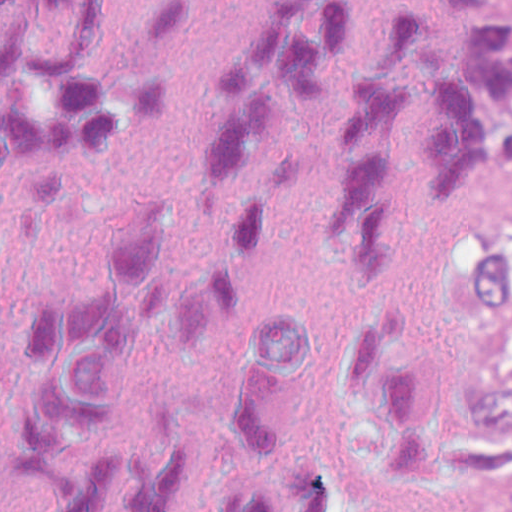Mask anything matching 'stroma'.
Returning <instances> with one entry per match:
<instances>
[{
    "mask_svg": "<svg viewBox=\"0 0 512 512\" xmlns=\"http://www.w3.org/2000/svg\"><path fill=\"white\" fill-rule=\"evenodd\" d=\"M512 216V151L488 166L472 188L466 221ZM429 512H464L447 473L435 417L429 441Z\"/></svg>",
    "mask_w": 512,
    "mask_h": 512,
    "instance_id": "35a3bbf8",
    "label": "stroma"
}]
</instances>
